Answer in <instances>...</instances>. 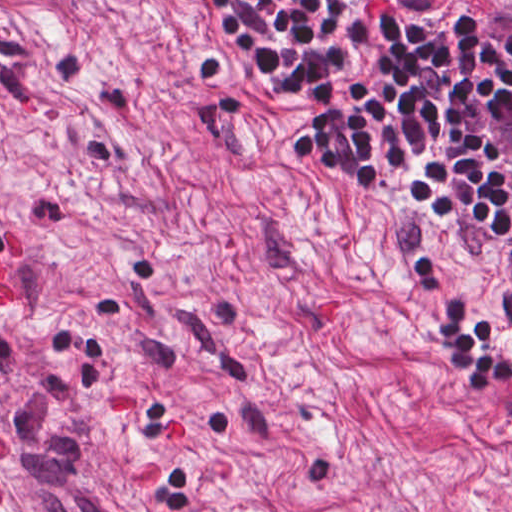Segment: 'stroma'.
<instances>
[{"label":"stroma","instance_id":"1","mask_svg":"<svg viewBox=\"0 0 512 512\" xmlns=\"http://www.w3.org/2000/svg\"><path fill=\"white\" fill-rule=\"evenodd\" d=\"M0 261V512H512V401L66 0H0Z\"/></svg>","mask_w":512,"mask_h":512}]
</instances>
